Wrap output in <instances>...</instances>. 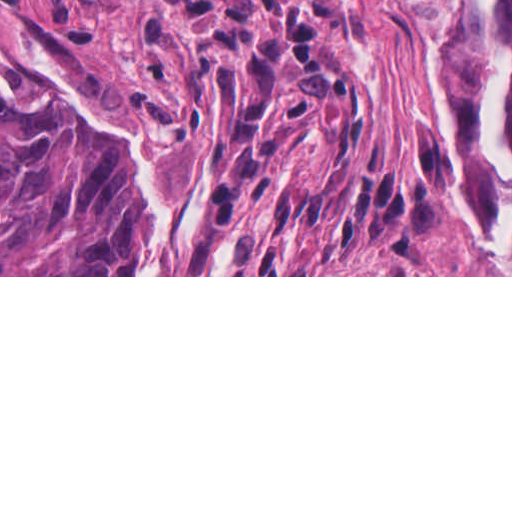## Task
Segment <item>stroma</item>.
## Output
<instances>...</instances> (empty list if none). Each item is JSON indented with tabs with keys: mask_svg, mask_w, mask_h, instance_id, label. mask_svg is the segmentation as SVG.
<instances>
[{
	"mask_svg": "<svg viewBox=\"0 0 512 512\" xmlns=\"http://www.w3.org/2000/svg\"><path fill=\"white\" fill-rule=\"evenodd\" d=\"M336 3L319 18L335 61L364 92L363 161L407 185L440 190L435 228L407 249L331 253L335 275H184L192 252L164 275H129L140 248L123 275L0 277H512L488 273L481 196L444 128L425 28L403 0ZM0 42L43 54L127 123L172 134L168 199L189 197L205 211L199 191L212 123L200 110L175 19L125 0H0Z\"/></svg>",
	"mask_w": 512,
	"mask_h": 512,
	"instance_id": "35a3bbf8",
	"label": "stroma"
}]
</instances>
